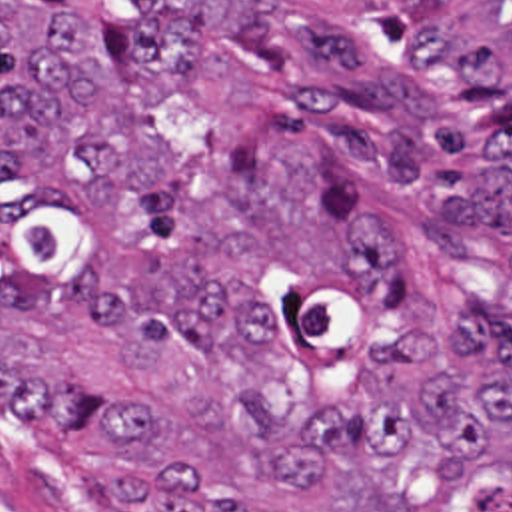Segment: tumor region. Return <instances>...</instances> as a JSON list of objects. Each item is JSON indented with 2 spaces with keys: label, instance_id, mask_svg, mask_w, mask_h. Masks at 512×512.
Segmentation results:
<instances>
[{
  "label": "tumor region",
  "instance_id": "obj_1",
  "mask_svg": "<svg viewBox=\"0 0 512 512\" xmlns=\"http://www.w3.org/2000/svg\"><path fill=\"white\" fill-rule=\"evenodd\" d=\"M0 389L109 512H512V0H0Z\"/></svg>",
  "mask_w": 512,
  "mask_h": 512
}]
</instances>
